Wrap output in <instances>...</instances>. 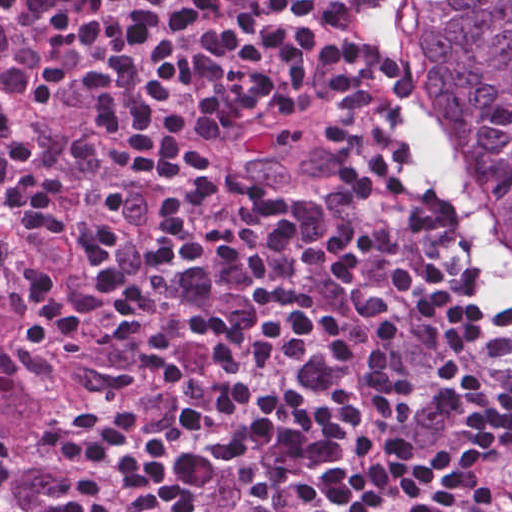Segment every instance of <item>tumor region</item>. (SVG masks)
<instances>
[{
  "mask_svg": "<svg viewBox=\"0 0 512 512\" xmlns=\"http://www.w3.org/2000/svg\"><path fill=\"white\" fill-rule=\"evenodd\" d=\"M37 26L31 0L0 16V101L32 137ZM0 226L16 255L0 275V512H52L29 477L34 462L75 417L92 380L65 348L31 286L33 230L0 197Z\"/></svg>",
  "mask_w": 512,
  "mask_h": 512,
  "instance_id": "tumor-region-1",
  "label": "tumor region"
}]
</instances>
